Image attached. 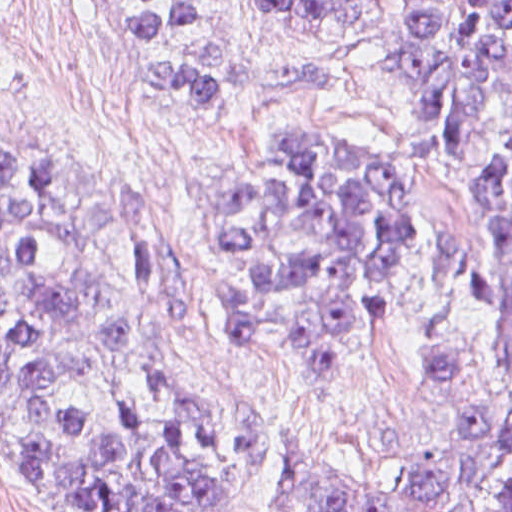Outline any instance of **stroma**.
Wrapping results in <instances>:
<instances>
[{
    "instance_id": "obj_1",
    "label": "stroma",
    "mask_w": 512,
    "mask_h": 512,
    "mask_svg": "<svg viewBox=\"0 0 512 512\" xmlns=\"http://www.w3.org/2000/svg\"><path fill=\"white\" fill-rule=\"evenodd\" d=\"M174 1L100 18L152 17ZM192 2L197 18L135 60L209 44L244 70L329 65L337 82L275 102H225L185 130L106 38L87 0H10L0 15V116L73 175L104 243L145 297L168 361L238 404L243 512H302L287 449L315 446L420 485L432 467L509 421L500 325L512 305V249L473 170L512 130V68L471 125L461 157L435 136H415V108L384 57L398 0H354L341 23L323 26L277 21L263 0ZM281 135L355 137L392 155L414 144L421 225L410 314L401 335L365 358L361 384L345 399L245 347L224 297V172ZM57 500L52 468L0 399V512H55Z\"/></svg>"
}]
</instances>
